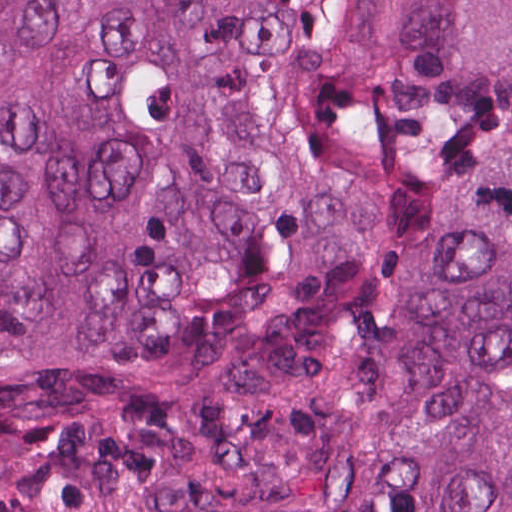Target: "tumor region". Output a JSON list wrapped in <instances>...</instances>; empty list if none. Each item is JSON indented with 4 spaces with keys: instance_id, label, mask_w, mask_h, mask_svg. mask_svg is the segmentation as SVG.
<instances>
[{
    "instance_id": "e687c5a6",
    "label": "tumor region",
    "mask_w": 512,
    "mask_h": 512,
    "mask_svg": "<svg viewBox=\"0 0 512 512\" xmlns=\"http://www.w3.org/2000/svg\"><path fill=\"white\" fill-rule=\"evenodd\" d=\"M0 512H512V0L0 1Z\"/></svg>"
}]
</instances>
